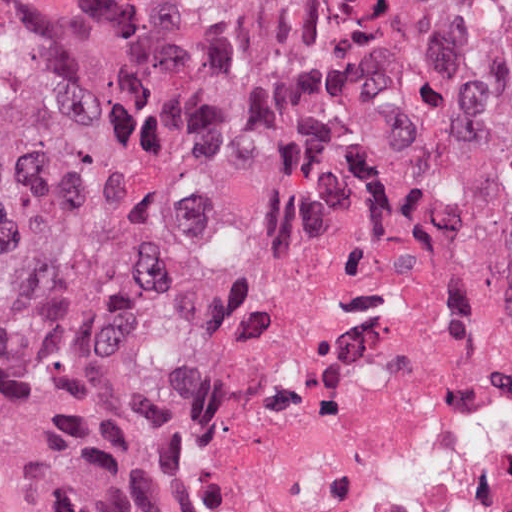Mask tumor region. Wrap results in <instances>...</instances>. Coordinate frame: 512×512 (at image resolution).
<instances>
[{"mask_svg": "<svg viewBox=\"0 0 512 512\" xmlns=\"http://www.w3.org/2000/svg\"><path fill=\"white\" fill-rule=\"evenodd\" d=\"M322 198L455 220L512 286V0H0V494L160 512L124 316Z\"/></svg>", "mask_w": 512, "mask_h": 512, "instance_id": "1", "label": "tumor region"}]
</instances>
